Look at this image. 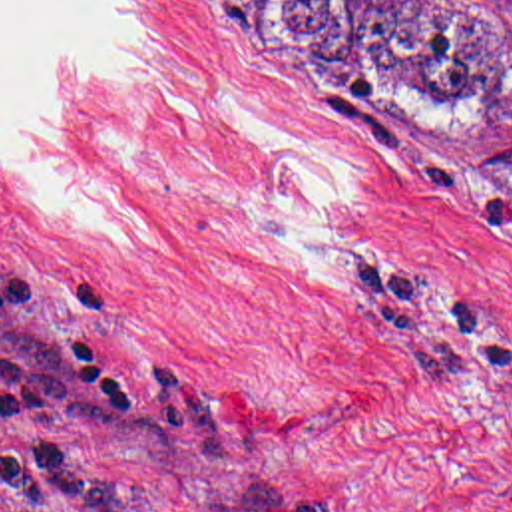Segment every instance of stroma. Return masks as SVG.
I'll return each instance as SVG.
<instances>
[{
    "label": "stroma",
    "mask_w": 512,
    "mask_h": 512,
    "mask_svg": "<svg viewBox=\"0 0 512 512\" xmlns=\"http://www.w3.org/2000/svg\"><path fill=\"white\" fill-rule=\"evenodd\" d=\"M63 121L134 220L0 151V280L73 298L130 380L0 322L3 512H512V139L361 101L228 0H118Z\"/></svg>",
    "instance_id": "obj_1"
}]
</instances>
